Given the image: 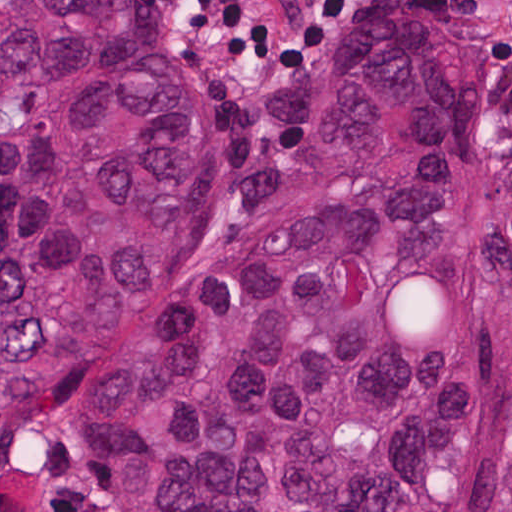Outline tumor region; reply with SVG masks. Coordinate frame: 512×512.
I'll list each match as a JSON object with an SVG mask.
<instances>
[{"label":"tumor region","mask_w":512,"mask_h":512,"mask_svg":"<svg viewBox=\"0 0 512 512\" xmlns=\"http://www.w3.org/2000/svg\"><path fill=\"white\" fill-rule=\"evenodd\" d=\"M250 119L283 171L195 249L214 133L151 0H1V427L65 387L114 512H512V162L479 209L453 22L347 15Z\"/></svg>","instance_id":"1"}]
</instances>
